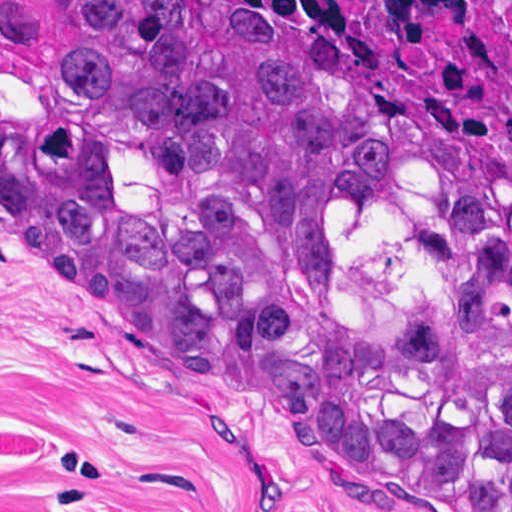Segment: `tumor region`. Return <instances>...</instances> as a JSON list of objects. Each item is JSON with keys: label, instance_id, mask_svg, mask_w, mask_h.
<instances>
[{"label": "tumor region", "instance_id": "e687c5a6", "mask_svg": "<svg viewBox=\"0 0 512 512\" xmlns=\"http://www.w3.org/2000/svg\"><path fill=\"white\" fill-rule=\"evenodd\" d=\"M0 242L459 512H512V168L297 10L0 0Z\"/></svg>", "mask_w": 512, "mask_h": 512}]
</instances>
